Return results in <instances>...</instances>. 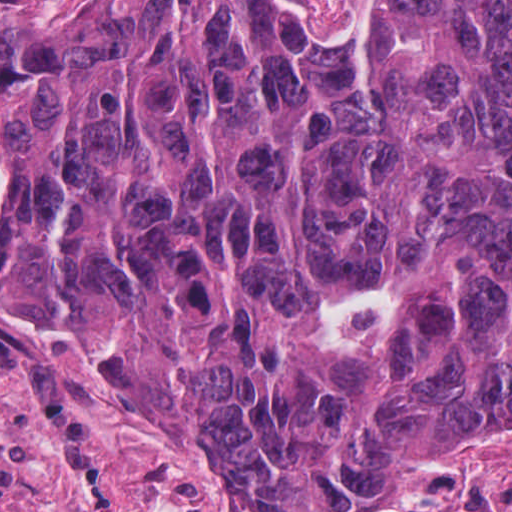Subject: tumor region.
<instances>
[{
  "label": "tumor region",
  "mask_w": 512,
  "mask_h": 512,
  "mask_svg": "<svg viewBox=\"0 0 512 512\" xmlns=\"http://www.w3.org/2000/svg\"><path fill=\"white\" fill-rule=\"evenodd\" d=\"M0 151V265L252 484L512 415V0H0Z\"/></svg>",
  "instance_id": "e687c5a6"
}]
</instances>
